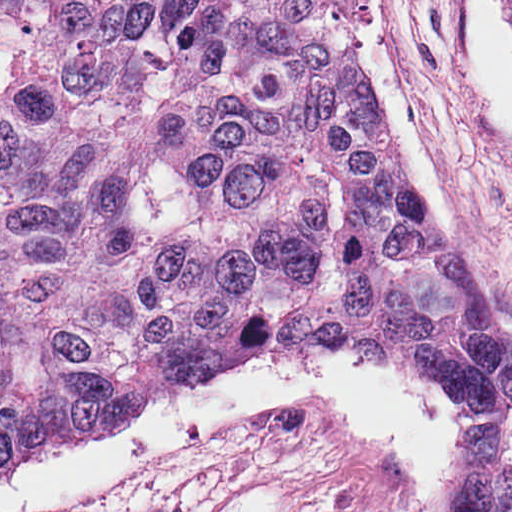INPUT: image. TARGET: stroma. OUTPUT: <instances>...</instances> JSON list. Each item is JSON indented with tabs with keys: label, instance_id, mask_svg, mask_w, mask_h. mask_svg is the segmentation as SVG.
Returning <instances> with one entry per match:
<instances>
[{
	"label": "stroma",
	"instance_id": "obj_1",
	"mask_svg": "<svg viewBox=\"0 0 512 512\" xmlns=\"http://www.w3.org/2000/svg\"><path fill=\"white\" fill-rule=\"evenodd\" d=\"M0 512H258L198 376L165 385L131 438L43 453L0 480Z\"/></svg>",
	"mask_w": 512,
	"mask_h": 512
}]
</instances>
